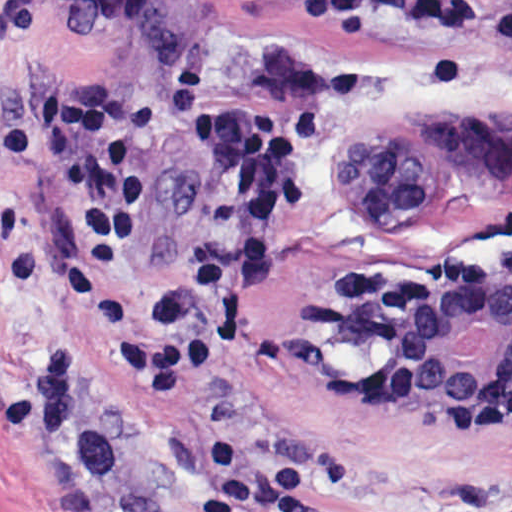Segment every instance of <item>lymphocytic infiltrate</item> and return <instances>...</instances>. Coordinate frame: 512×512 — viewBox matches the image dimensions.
Masks as SVG:
<instances>
[{
	"instance_id": "f902f5d3",
	"label": "lymphocytic infiltrate",
	"mask_w": 512,
	"mask_h": 512,
	"mask_svg": "<svg viewBox=\"0 0 512 512\" xmlns=\"http://www.w3.org/2000/svg\"><path fill=\"white\" fill-rule=\"evenodd\" d=\"M328 24L396 22L464 26L478 0H285ZM512 58V12L502 21ZM171 124L223 175L231 241L170 276L157 291L160 316L144 341L146 379L185 383L208 365L229 334L261 302L281 242L311 193L320 139L315 108L230 100L213 71L185 65L126 93L61 85L41 97L35 123L0 132V168L52 175L70 201L74 253L87 283L112 281L147 232L167 186L153 131ZM214 474L201 488V512H317L304 477L285 472L235 441L207 444Z\"/></svg>"
}]
</instances>
